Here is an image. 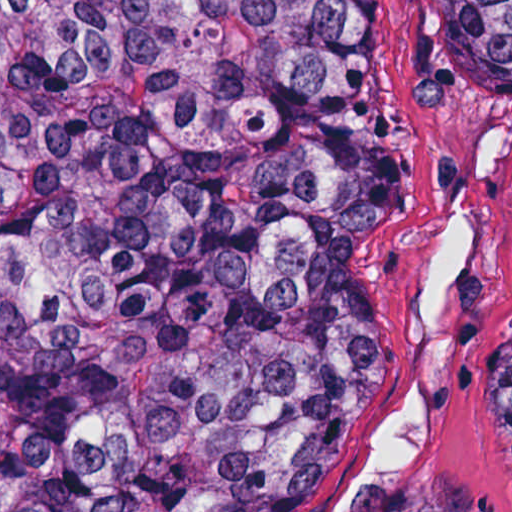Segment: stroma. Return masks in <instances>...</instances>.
Returning a JSON list of instances; mask_svg holds the SVG:
<instances>
[{
    "mask_svg": "<svg viewBox=\"0 0 512 512\" xmlns=\"http://www.w3.org/2000/svg\"><path fill=\"white\" fill-rule=\"evenodd\" d=\"M402 190L366 248L388 389L291 512H512L486 353L512 324V93H485L445 0H360Z\"/></svg>",
    "mask_w": 512,
    "mask_h": 512,
    "instance_id": "obj_1",
    "label": "stroma"
}]
</instances>
